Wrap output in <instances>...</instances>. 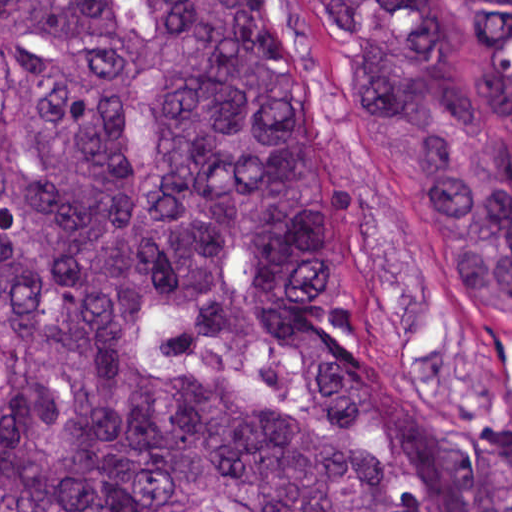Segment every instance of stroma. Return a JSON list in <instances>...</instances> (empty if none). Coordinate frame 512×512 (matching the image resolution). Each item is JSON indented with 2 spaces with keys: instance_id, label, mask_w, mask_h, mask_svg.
<instances>
[{
  "instance_id": "1",
  "label": "stroma",
  "mask_w": 512,
  "mask_h": 512,
  "mask_svg": "<svg viewBox=\"0 0 512 512\" xmlns=\"http://www.w3.org/2000/svg\"><path fill=\"white\" fill-rule=\"evenodd\" d=\"M476 32L462 0H426ZM259 55L308 106L331 158V311L337 352L398 445L474 460L512 418V329L446 293L419 225L346 111L318 0H259Z\"/></svg>"
}]
</instances>
